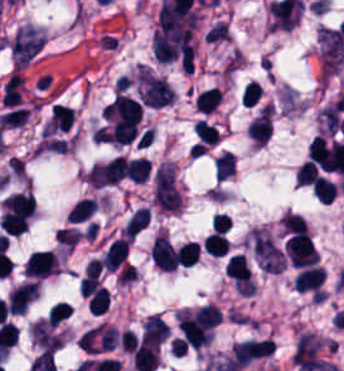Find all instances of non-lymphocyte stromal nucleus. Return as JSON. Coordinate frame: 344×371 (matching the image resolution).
Segmentation results:
<instances>
[{
  "instance_id": "obj_3",
  "label": "non-lymphocyte stromal nucleus",
  "mask_w": 344,
  "mask_h": 371,
  "mask_svg": "<svg viewBox=\"0 0 344 371\" xmlns=\"http://www.w3.org/2000/svg\"><path fill=\"white\" fill-rule=\"evenodd\" d=\"M137 81L140 98L145 105L160 107L173 101L171 87L163 78L147 71H139Z\"/></svg>"
},
{
  "instance_id": "obj_2",
  "label": "non-lymphocyte stromal nucleus",
  "mask_w": 344,
  "mask_h": 371,
  "mask_svg": "<svg viewBox=\"0 0 344 371\" xmlns=\"http://www.w3.org/2000/svg\"><path fill=\"white\" fill-rule=\"evenodd\" d=\"M250 236L253 253L260 269L282 271L287 260L271 237L260 227H253Z\"/></svg>"
},
{
  "instance_id": "obj_1",
  "label": "non-lymphocyte stromal nucleus",
  "mask_w": 344,
  "mask_h": 371,
  "mask_svg": "<svg viewBox=\"0 0 344 371\" xmlns=\"http://www.w3.org/2000/svg\"><path fill=\"white\" fill-rule=\"evenodd\" d=\"M153 199L166 209L181 207V192L171 162H163L155 171Z\"/></svg>"
}]
</instances>
